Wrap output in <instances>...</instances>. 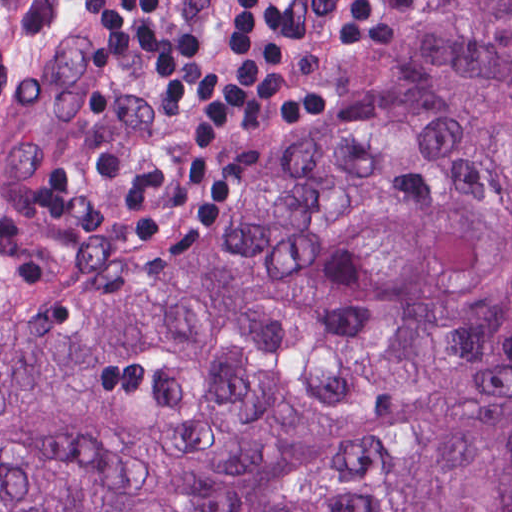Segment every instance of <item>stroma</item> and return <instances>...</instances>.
I'll list each match as a JSON object with an SVG mask.
<instances>
[{
	"instance_id": "35a3bbf8",
	"label": "stroma",
	"mask_w": 512,
	"mask_h": 512,
	"mask_svg": "<svg viewBox=\"0 0 512 512\" xmlns=\"http://www.w3.org/2000/svg\"><path fill=\"white\" fill-rule=\"evenodd\" d=\"M437 0H374L396 26L393 42L381 47L354 42H305L280 52L278 70L287 91H330L340 102L297 138L273 151L243 186L227 223L192 252H157L130 237H112L79 225L47 220L35 207L27 181L75 158L93 141L123 143L129 156L143 153L180 132L194 111L149 97L152 69L143 62L124 71L84 65L95 44L91 28L79 22L76 0H50V31L56 59L81 84L99 114L67 120L37 133L13 156V194L32 225L58 240L107 251L167 260L169 273L189 255L226 231L245 197L286 159L379 85L395 56L424 28ZM172 21L197 33L204 66L229 61L231 0H161Z\"/></svg>"
}]
</instances>
